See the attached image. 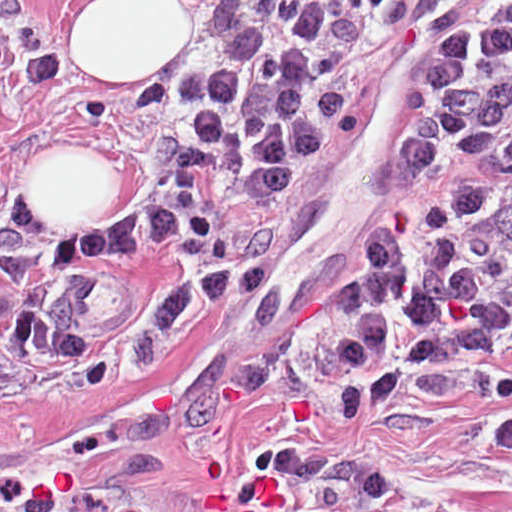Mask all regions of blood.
Instances as JSON below:
<instances>
[{"label": "blood", "instance_id": "1", "mask_svg": "<svg viewBox=\"0 0 512 512\" xmlns=\"http://www.w3.org/2000/svg\"><path fill=\"white\" fill-rule=\"evenodd\" d=\"M30 491L31 500H50L51 499V490L47 484H36Z\"/></svg>", "mask_w": 512, "mask_h": 512}]
</instances>
